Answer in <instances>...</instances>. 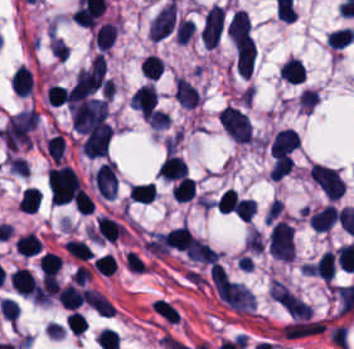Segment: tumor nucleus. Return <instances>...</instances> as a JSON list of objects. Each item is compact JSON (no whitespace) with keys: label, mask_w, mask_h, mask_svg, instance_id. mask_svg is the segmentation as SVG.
Returning <instances> with one entry per match:
<instances>
[{"label":"tumor nucleus","mask_w":354,"mask_h":349,"mask_svg":"<svg viewBox=\"0 0 354 349\" xmlns=\"http://www.w3.org/2000/svg\"><path fill=\"white\" fill-rule=\"evenodd\" d=\"M73 128L91 135L108 138L112 131L107 100L86 98L71 109Z\"/></svg>","instance_id":"1"},{"label":"tumor nucleus","mask_w":354,"mask_h":349,"mask_svg":"<svg viewBox=\"0 0 354 349\" xmlns=\"http://www.w3.org/2000/svg\"><path fill=\"white\" fill-rule=\"evenodd\" d=\"M268 248L277 258L292 262L295 253L294 229L283 221H275L270 230Z\"/></svg>","instance_id":"2"},{"label":"tumor nucleus","mask_w":354,"mask_h":349,"mask_svg":"<svg viewBox=\"0 0 354 349\" xmlns=\"http://www.w3.org/2000/svg\"><path fill=\"white\" fill-rule=\"evenodd\" d=\"M223 126L239 143H250L252 126L246 113L234 105H226L220 112Z\"/></svg>","instance_id":"3"},{"label":"tumor nucleus","mask_w":354,"mask_h":349,"mask_svg":"<svg viewBox=\"0 0 354 349\" xmlns=\"http://www.w3.org/2000/svg\"><path fill=\"white\" fill-rule=\"evenodd\" d=\"M321 191L330 198H340L345 191V183L337 171L314 164L308 170Z\"/></svg>","instance_id":"4"},{"label":"tumor nucleus","mask_w":354,"mask_h":349,"mask_svg":"<svg viewBox=\"0 0 354 349\" xmlns=\"http://www.w3.org/2000/svg\"><path fill=\"white\" fill-rule=\"evenodd\" d=\"M234 58L237 74L250 78L256 59V47L255 40L249 33L235 41Z\"/></svg>","instance_id":"5"},{"label":"tumor nucleus","mask_w":354,"mask_h":349,"mask_svg":"<svg viewBox=\"0 0 354 349\" xmlns=\"http://www.w3.org/2000/svg\"><path fill=\"white\" fill-rule=\"evenodd\" d=\"M92 178L98 194L112 200L117 188L115 163L102 162Z\"/></svg>","instance_id":"6"},{"label":"tumor nucleus","mask_w":354,"mask_h":349,"mask_svg":"<svg viewBox=\"0 0 354 349\" xmlns=\"http://www.w3.org/2000/svg\"><path fill=\"white\" fill-rule=\"evenodd\" d=\"M250 28V18L244 9H236L227 25V33L235 44Z\"/></svg>","instance_id":"7"}]
</instances>
